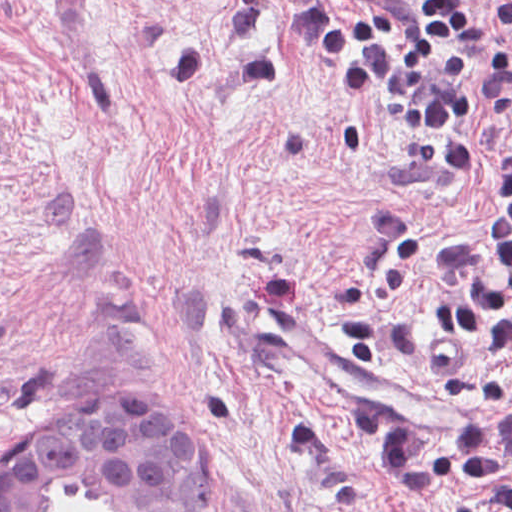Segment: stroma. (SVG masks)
<instances>
[{"label":"stroma","instance_id":"obj_1","mask_svg":"<svg viewBox=\"0 0 512 512\" xmlns=\"http://www.w3.org/2000/svg\"><path fill=\"white\" fill-rule=\"evenodd\" d=\"M344 1V0H339ZM288 0H0V470L70 410L139 397L174 410L208 461L213 512H499L443 489L392 500L408 430L313 378L346 350L340 296L384 258L375 223L412 218L442 260L495 210L487 97L510 45L485 9L467 176L406 172V127L354 113L288 45ZM425 343L376 363L464 407L512 380L490 347L435 366L448 295L413 274L386 294ZM69 485L45 512H103Z\"/></svg>","mask_w":512,"mask_h":512}]
</instances>
